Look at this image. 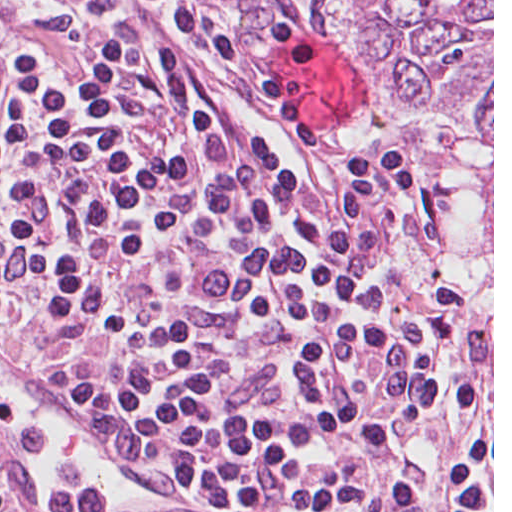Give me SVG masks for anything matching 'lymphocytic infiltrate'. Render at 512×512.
Returning a JSON list of instances; mask_svg holds the SVG:
<instances>
[{"label":"lymphocytic infiltrate","mask_w":512,"mask_h":512,"mask_svg":"<svg viewBox=\"0 0 512 512\" xmlns=\"http://www.w3.org/2000/svg\"><path fill=\"white\" fill-rule=\"evenodd\" d=\"M146 1L315 141L213 17ZM223 142L217 98L141 15L0 1V327L40 301L78 408L197 484L438 408L468 314L456 281L419 300L391 261L420 192L407 154L304 181L259 138L208 191ZM469 384L444 405L492 390Z\"/></svg>","instance_id":"f902f5d3"}]
</instances>
